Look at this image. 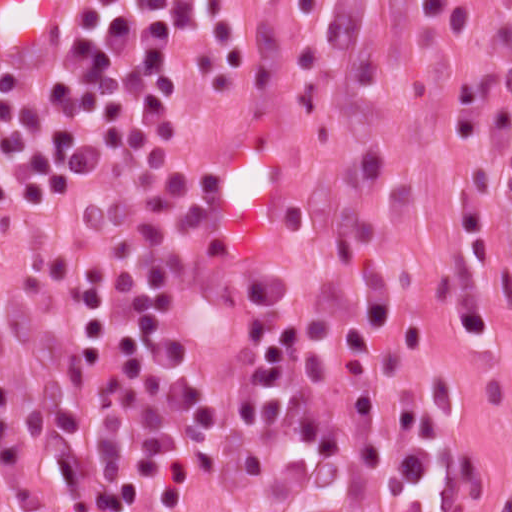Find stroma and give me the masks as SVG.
Returning <instances> with one entry per match:
<instances>
[{
    "mask_svg": "<svg viewBox=\"0 0 512 512\" xmlns=\"http://www.w3.org/2000/svg\"><path fill=\"white\" fill-rule=\"evenodd\" d=\"M469 1L470 19L454 32L456 19L417 0H322L307 20L295 0H234L251 48L243 75L216 97L203 75L207 40L178 38L173 112L124 158L191 139L204 141L205 166L220 139L265 120L292 176V208L264 240L283 265L302 257L316 274L339 247L378 254L387 339L372 397L417 395L427 411L432 462L418 512H512V197L490 155L483 338L460 325L450 289L451 217L471 156L453 96L495 76L503 103L512 99L491 33L503 2ZM183 145L196 210L201 164ZM104 200L0 214L1 366L36 371L46 298L96 232ZM182 333L209 371L207 439L170 512H258L267 417L250 313L197 309L182 315ZM47 512L85 511L50 502Z\"/></svg>",
    "mask_w": 512,
    "mask_h": 512,
    "instance_id": "1",
    "label": "stroma"
}]
</instances>
